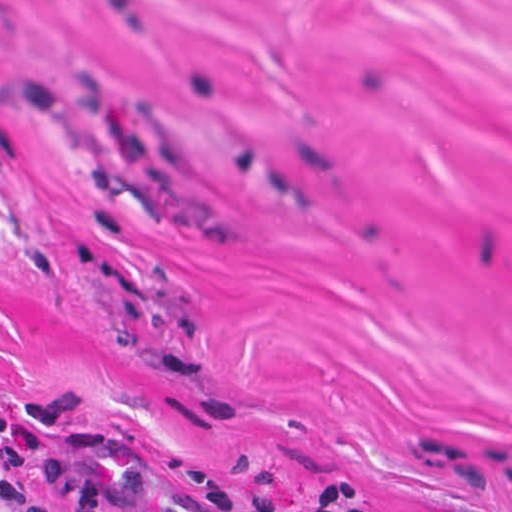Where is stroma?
Masks as SVG:
<instances>
[{
	"label": "stroma",
	"mask_w": 512,
	"mask_h": 512,
	"mask_svg": "<svg viewBox=\"0 0 512 512\" xmlns=\"http://www.w3.org/2000/svg\"><path fill=\"white\" fill-rule=\"evenodd\" d=\"M109 437L512 512V0H0V456Z\"/></svg>",
	"instance_id": "obj_1"
}]
</instances>
